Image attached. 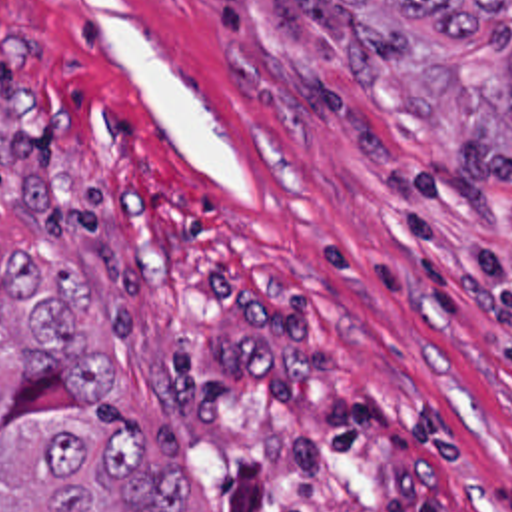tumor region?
<instances>
[{"label": "tumor region", "mask_w": 512, "mask_h": 512, "mask_svg": "<svg viewBox=\"0 0 512 512\" xmlns=\"http://www.w3.org/2000/svg\"><path fill=\"white\" fill-rule=\"evenodd\" d=\"M349 75L512 153V0H315ZM0 512H189L175 426L111 400L113 356L81 332L85 273L9 247L0 265Z\"/></svg>", "instance_id": "e687c5a6"}]
</instances>
